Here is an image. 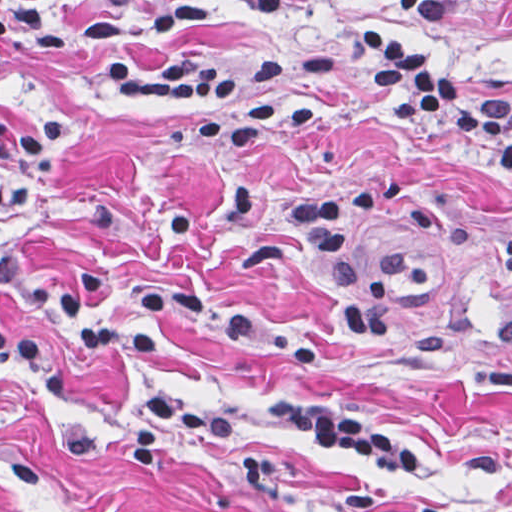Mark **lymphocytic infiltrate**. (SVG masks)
I'll use <instances>...</instances> for the list:
<instances>
[{
    "label": "lymphocytic infiltrate",
    "mask_w": 512,
    "mask_h": 512,
    "mask_svg": "<svg viewBox=\"0 0 512 512\" xmlns=\"http://www.w3.org/2000/svg\"><path fill=\"white\" fill-rule=\"evenodd\" d=\"M46 0H0V49L6 42L41 35ZM252 13H272L284 0H242ZM492 0H420L429 23L452 25ZM212 0H152L130 19H93L78 25L84 42H102L97 59L125 100L190 113L194 139L213 152H236L275 132L305 130L317 118L312 106H277L252 97L288 75L325 73L341 62L357 68L402 122L459 129L481 158L488 177L512 178V100L453 77L434 57L397 33L369 30L348 35L312 56L270 52L247 68L200 56L164 59L151 68L129 63L117 42L150 38L175 23H195ZM69 110L0 122V295L35 320L0 304V366L33 389L63 388L60 356L90 363H132L160 349L167 331L208 300L205 283L190 277L156 280L138 298L133 316L108 300V267L70 271L21 254L12 240L13 211L26 205L55 175L73 146ZM268 407L293 435L362 462L439 470L435 459L407 441L346 413L322 411L301 399L269 394ZM235 417L212 424L192 420L185 397L151 385L140 413L121 442L122 461L143 472L170 436H219Z\"/></svg>",
    "instance_id": "obj_1"
}]
</instances>
